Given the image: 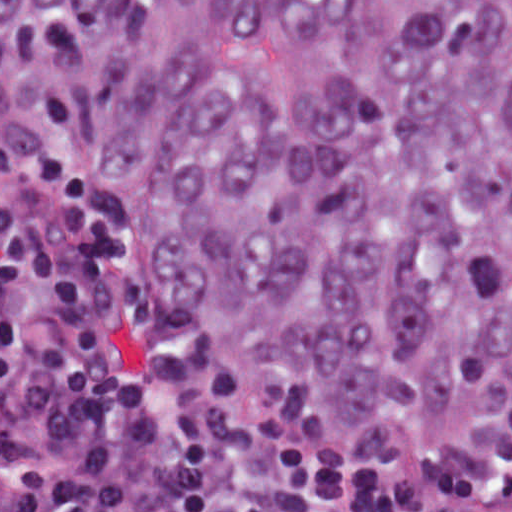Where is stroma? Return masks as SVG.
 <instances>
[{"mask_svg":"<svg viewBox=\"0 0 512 512\" xmlns=\"http://www.w3.org/2000/svg\"><path fill=\"white\" fill-rule=\"evenodd\" d=\"M0 96L15 112L23 125L31 134L39 149L50 164L53 173L60 178L69 189L74 200L102 226H105L115 236L124 242L117 230L109 226L97 207L95 206L86 183L61 135L44 119L22 89L0 62ZM125 244V242H124ZM126 245V244H125ZM127 246V245H126ZM128 248V247H127ZM129 249V248H128ZM512 412V408L506 412L490 415L482 420L493 418ZM480 420V421H482ZM467 425V424H465ZM463 426V425H460ZM458 426V427H460ZM455 427L438 434L418 447L414 452L418 453L434 439L458 428ZM364 458H395L409 454H358Z\"/></svg>","mask_w":512,"mask_h":512,"instance_id":"stroma-1","label":"stroma"}]
</instances>
